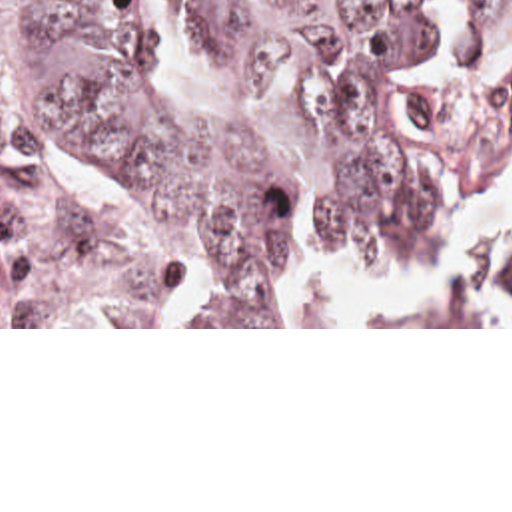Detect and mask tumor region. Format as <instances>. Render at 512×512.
<instances>
[{"label":"tumor region","instance_id":"tumor-region-1","mask_svg":"<svg viewBox=\"0 0 512 512\" xmlns=\"http://www.w3.org/2000/svg\"><path fill=\"white\" fill-rule=\"evenodd\" d=\"M0 6L16 24L21 107L0 121V325H273L301 203L345 259L389 265L453 221L437 179L491 183L512 157V0H473L465 55L509 57L479 135L459 131L443 91L401 83L433 34L425 0H183L195 48L291 83V111L245 139L145 97L143 36L121 0ZM63 161L207 243L195 315H171L179 269L59 189ZM483 253L471 247L463 285L415 325H512V307L485 317L469 303ZM501 283L512 305V263Z\"/></svg>","mask_w":512,"mask_h":512}]
</instances>
